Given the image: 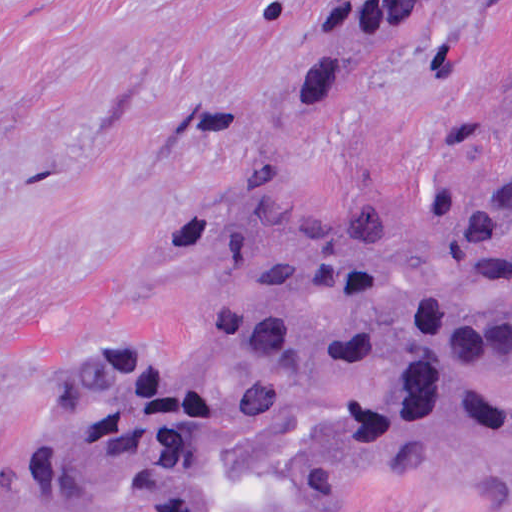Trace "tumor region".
Masks as SVG:
<instances>
[{
  "mask_svg": "<svg viewBox=\"0 0 512 512\" xmlns=\"http://www.w3.org/2000/svg\"><path fill=\"white\" fill-rule=\"evenodd\" d=\"M433 6L364 8L289 63L293 111L340 103ZM512 137V86L474 119ZM512 162L317 216L224 197L167 272L191 357L74 358L31 414L18 494L57 512H330L416 469L512 512Z\"/></svg>",
  "mask_w": 512,
  "mask_h": 512,
  "instance_id": "obj_1",
  "label": "tumor region"
}]
</instances>
